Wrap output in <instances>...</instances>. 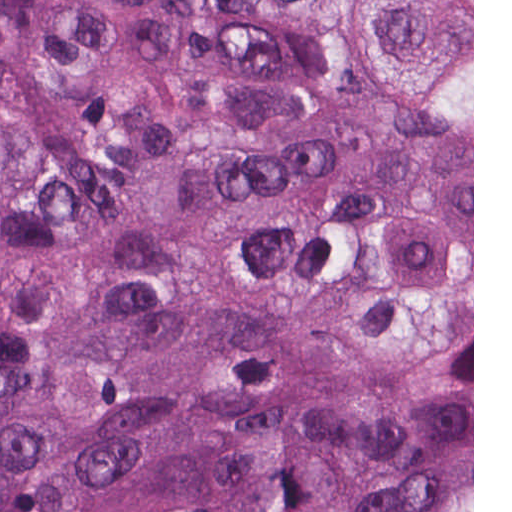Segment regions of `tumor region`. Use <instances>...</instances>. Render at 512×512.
<instances>
[{
    "label": "tumor region",
    "mask_w": 512,
    "mask_h": 512,
    "mask_svg": "<svg viewBox=\"0 0 512 512\" xmlns=\"http://www.w3.org/2000/svg\"><path fill=\"white\" fill-rule=\"evenodd\" d=\"M0 512H472V0H0Z\"/></svg>",
    "instance_id": "1"
}]
</instances>
